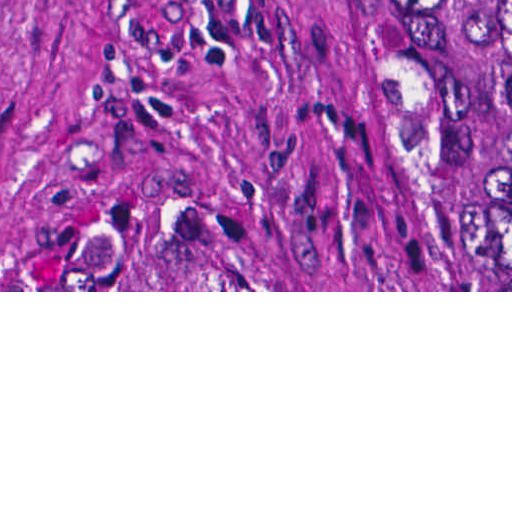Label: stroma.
<instances>
[{"instance_id": "35a3bbf8", "label": "stroma", "mask_w": 512, "mask_h": 512, "mask_svg": "<svg viewBox=\"0 0 512 512\" xmlns=\"http://www.w3.org/2000/svg\"><path fill=\"white\" fill-rule=\"evenodd\" d=\"M403 0H0V292L479 291L478 147ZM201 217L244 290H2Z\"/></svg>"}]
</instances>
